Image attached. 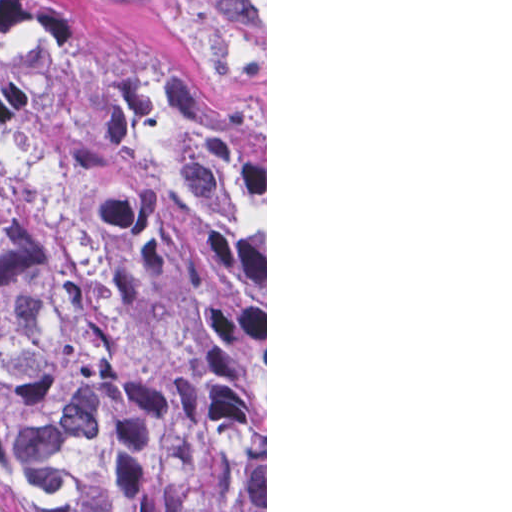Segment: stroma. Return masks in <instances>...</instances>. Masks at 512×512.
Returning <instances> with one entry per match:
<instances>
[{
	"mask_svg": "<svg viewBox=\"0 0 512 512\" xmlns=\"http://www.w3.org/2000/svg\"><path fill=\"white\" fill-rule=\"evenodd\" d=\"M116 45L183 68L256 143L265 174V512H267V0H59Z\"/></svg>",
	"mask_w": 512,
	"mask_h": 512,
	"instance_id": "35a3bbf8",
	"label": "stroma"
}]
</instances>
